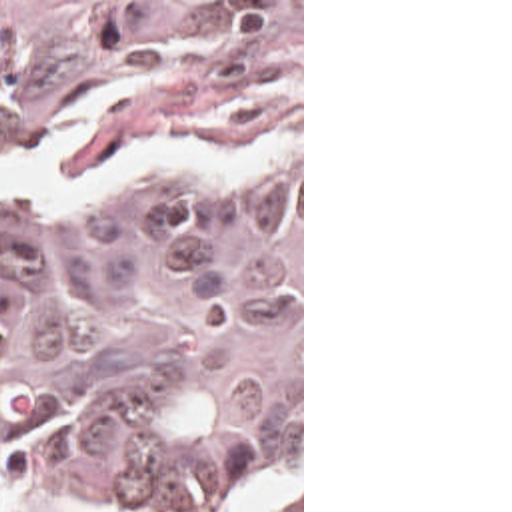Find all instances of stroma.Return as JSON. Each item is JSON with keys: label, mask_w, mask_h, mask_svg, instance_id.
<instances>
[{"label": "stroma", "mask_w": 512, "mask_h": 512, "mask_svg": "<svg viewBox=\"0 0 512 512\" xmlns=\"http://www.w3.org/2000/svg\"><path fill=\"white\" fill-rule=\"evenodd\" d=\"M0 2H300V373L288 397V433L266 485L248 512H272L300 493L304 512V0H0ZM0 512H106L70 495H0Z\"/></svg>", "instance_id": "35a3bbf8"}]
</instances>
